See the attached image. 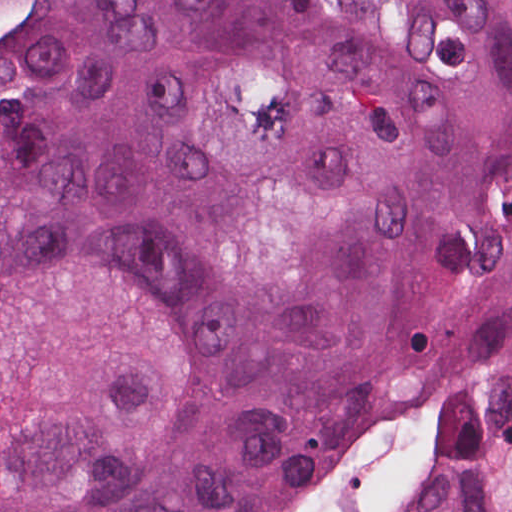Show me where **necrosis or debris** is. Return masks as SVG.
<instances>
[{
	"label": "necrosis or debris",
	"mask_w": 512,
	"mask_h": 512,
	"mask_svg": "<svg viewBox=\"0 0 512 512\" xmlns=\"http://www.w3.org/2000/svg\"><path fill=\"white\" fill-rule=\"evenodd\" d=\"M16 0H0V51L10 39V28Z\"/></svg>",
	"instance_id": "obj_1"
}]
</instances>
